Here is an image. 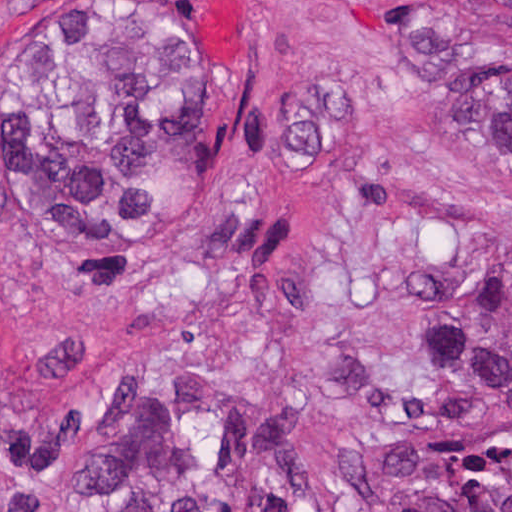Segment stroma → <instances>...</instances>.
<instances>
[{"mask_svg": "<svg viewBox=\"0 0 512 512\" xmlns=\"http://www.w3.org/2000/svg\"><path fill=\"white\" fill-rule=\"evenodd\" d=\"M416 11L512 67L485 0H0V491L171 434L216 512H337L398 450L493 442L437 315L512 268V180L410 59ZM57 30L198 40L201 207L165 235L31 215L27 60Z\"/></svg>", "mask_w": 512, "mask_h": 512, "instance_id": "stroma-1", "label": "stroma"}]
</instances>
